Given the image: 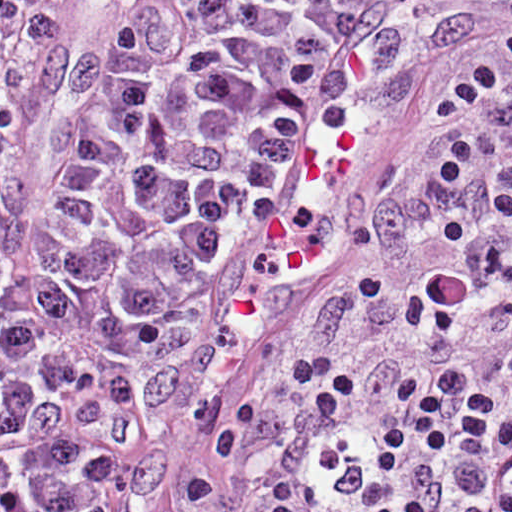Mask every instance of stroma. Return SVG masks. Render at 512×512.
<instances>
[{
    "label": "stroma",
    "mask_w": 512,
    "mask_h": 512,
    "mask_svg": "<svg viewBox=\"0 0 512 512\" xmlns=\"http://www.w3.org/2000/svg\"><path fill=\"white\" fill-rule=\"evenodd\" d=\"M410 46L416 112L305 279L180 316L98 512H417L512 271V0H336Z\"/></svg>",
    "instance_id": "35a3bbf8"
}]
</instances>
